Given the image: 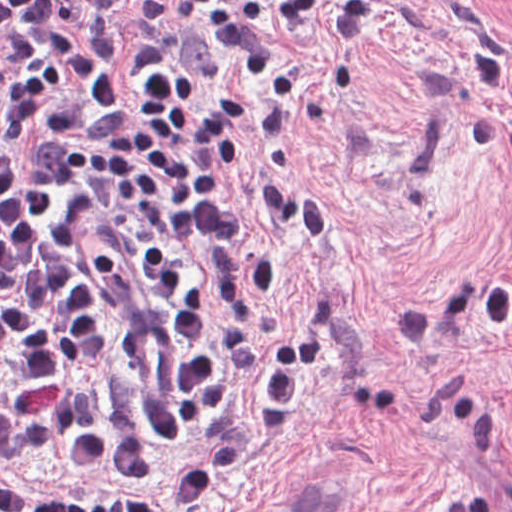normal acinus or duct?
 <instances>
[{
    "mask_svg": "<svg viewBox=\"0 0 512 512\" xmlns=\"http://www.w3.org/2000/svg\"><path fill=\"white\" fill-rule=\"evenodd\" d=\"M321 503H306L289 512H359L345 496L322 489H302Z\"/></svg>",
    "mask_w": 512,
    "mask_h": 512,
    "instance_id": "1",
    "label": "normal acinus or duct"
}]
</instances>
